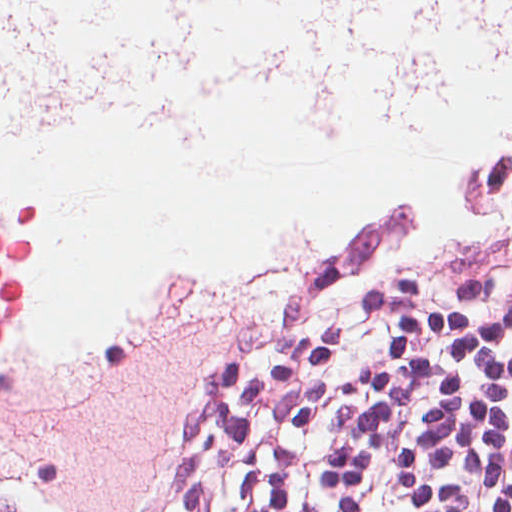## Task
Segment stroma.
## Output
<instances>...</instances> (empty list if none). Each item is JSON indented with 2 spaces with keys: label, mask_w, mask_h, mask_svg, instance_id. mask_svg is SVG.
I'll return each mask as SVG.
<instances>
[{
  "label": "stroma",
  "mask_w": 512,
  "mask_h": 512,
  "mask_svg": "<svg viewBox=\"0 0 512 512\" xmlns=\"http://www.w3.org/2000/svg\"><path fill=\"white\" fill-rule=\"evenodd\" d=\"M489 222L446 253L433 278L489 286L512 282V210Z\"/></svg>",
  "instance_id": "stroma-1"
}]
</instances>
